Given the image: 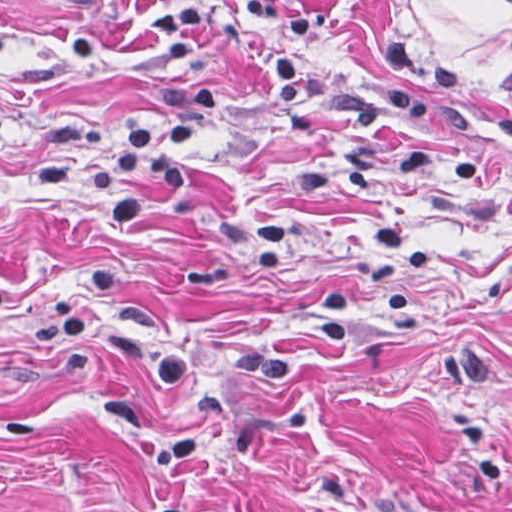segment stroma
<instances>
[{"label": "stroma", "instance_id": "35a3bbf8", "mask_svg": "<svg viewBox=\"0 0 512 512\" xmlns=\"http://www.w3.org/2000/svg\"><path fill=\"white\" fill-rule=\"evenodd\" d=\"M0 512H512V0H0Z\"/></svg>", "mask_w": 512, "mask_h": 512}]
</instances>
